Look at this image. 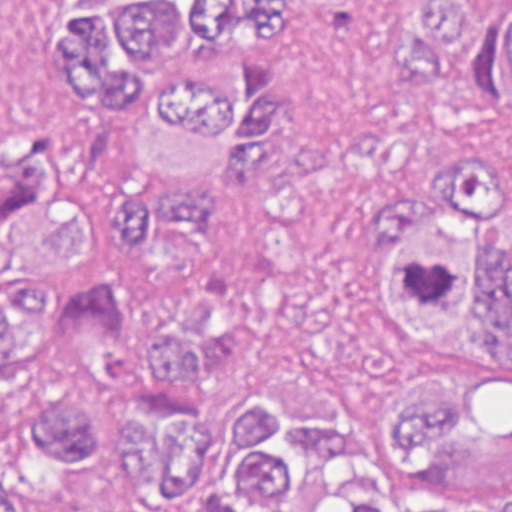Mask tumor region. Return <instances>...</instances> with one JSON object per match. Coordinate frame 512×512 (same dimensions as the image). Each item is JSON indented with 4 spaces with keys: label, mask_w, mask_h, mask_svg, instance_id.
<instances>
[{
    "label": "tumor region",
    "mask_w": 512,
    "mask_h": 512,
    "mask_svg": "<svg viewBox=\"0 0 512 512\" xmlns=\"http://www.w3.org/2000/svg\"><path fill=\"white\" fill-rule=\"evenodd\" d=\"M276 0H138V73L89 193L0 231V422L35 458L96 446L97 379L132 304L80 240L196 232L285 97ZM394 68L435 137L352 213L331 258L162 313L126 357L135 494L177 512H512V0H407ZM352 324L397 387L367 442L314 363L260 369L293 333ZM0 512H25L0 476Z\"/></svg>",
    "instance_id": "tumor-region-1"
}]
</instances>
